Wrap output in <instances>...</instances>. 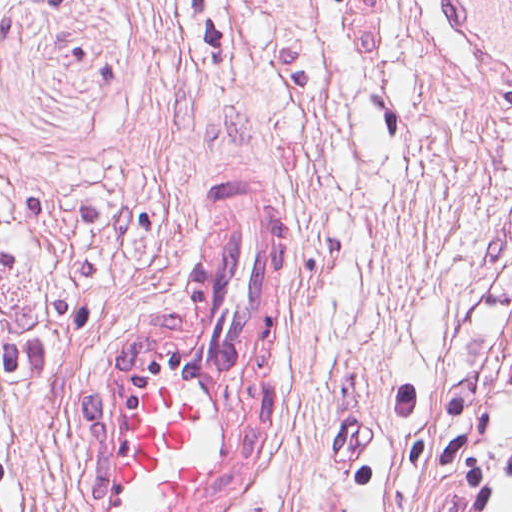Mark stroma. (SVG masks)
Instances as JSON below:
<instances>
[{
  "label": "stroma",
  "mask_w": 512,
  "mask_h": 512,
  "mask_svg": "<svg viewBox=\"0 0 512 512\" xmlns=\"http://www.w3.org/2000/svg\"><path fill=\"white\" fill-rule=\"evenodd\" d=\"M0 168L32 236L0 322L60 359L12 388L0 512H80L83 380L207 193L285 178L269 449L224 512H446L395 412L512 349V101L435 0H0Z\"/></svg>",
  "instance_id": "1"
}]
</instances>
